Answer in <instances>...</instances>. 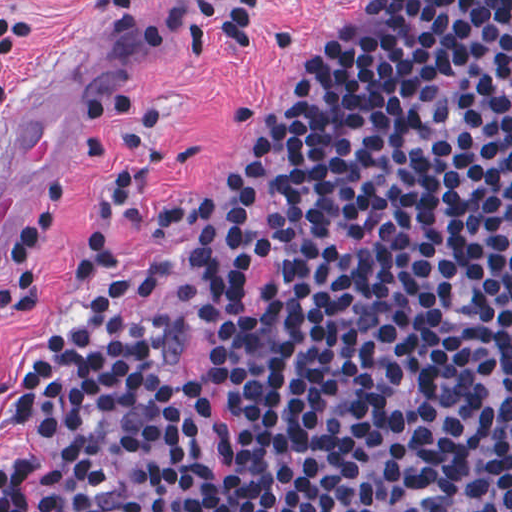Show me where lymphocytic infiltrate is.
<instances>
[{"instance_id":"1","label":"lymphocytic infiltrate","mask_w":512,"mask_h":512,"mask_svg":"<svg viewBox=\"0 0 512 512\" xmlns=\"http://www.w3.org/2000/svg\"><path fill=\"white\" fill-rule=\"evenodd\" d=\"M178 1L146 38L254 42L261 0ZM23 28L0 13V114ZM157 118L138 110L107 206L182 240L210 291L275 267L264 307L202 316L222 459L185 420L172 332L129 304L160 280L90 223L73 319L0 375V420L33 453L0 468V512H512V0H384L301 91L236 107L248 137L196 190L139 186ZM76 212L68 174L14 211L0 329L36 322Z\"/></svg>"}]
</instances>
